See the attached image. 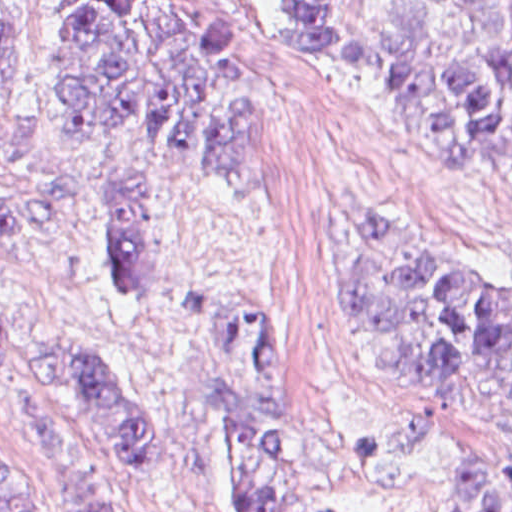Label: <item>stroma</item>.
<instances>
[{
  "label": "stroma",
  "mask_w": 512,
  "mask_h": 512,
  "mask_svg": "<svg viewBox=\"0 0 512 512\" xmlns=\"http://www.w3.org/2000/svg\"><path fill=\"white\" fill-rule=\"evenodd\" d=\"M71 1L38 0L35 40L0 121V187L132 183L156 217L154 288L141 300L109 298L83 257L8 246L0 291L132 374L161 461L122 463L78 404L0 371V470L31 490V512H54L59 490L30 437L37 426L91 453L120 512H225L223 453L196 387L219 344L215 312L231 302L271 340L323 510L455 512L452 456H512V431L383 376L342 274L358 218L376 208L512 283V181L487 164L441 171L416 154L374 61L375 0H226L231 59L252 92V175L242 188L127 128L57 127L43 119L38 91Z\"/></svg>",
  "instance_id": "1"
}]
</instances>
